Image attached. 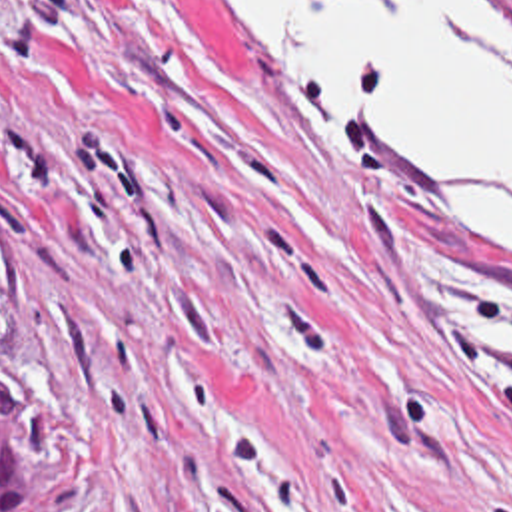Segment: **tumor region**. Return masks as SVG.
<instances>
[{
  "mask_svg": "<svg viewBox=\"0 0 512 512\" xmlns=\"http://www.w3.org/2000/svg\"><path fill=\"white\" fill-rule=\"evenodd\" d=\"M0 512H54V449L36 407L0 403Z\"/></svg>",
  "mask_w": 512,
  "mask_h": 512,
  "instance_id": "1",
  "label": "tumor region"
}]
</instances>
